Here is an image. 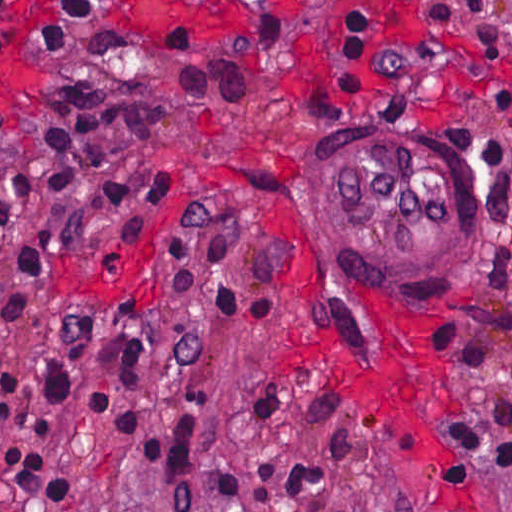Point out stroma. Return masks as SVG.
<instances>
[{"instance_id": "obj_1", "label": "stroma", "mask_w": 512, "mask_h": 512, "mask_svg": "<svg viewBox=\"0 0 512 512\" xmlns=\"http://www.w3.org/2000/svg\"><path fill=\"white\" fill-rule=\"evenodd\" d=\"M55 0H13L20 32ZM117 29L196 26L209 42L277 20L287 50L252 94L225 106H170L144 141L104 157L110 177L172 173L178 194L147 211L58 236L47 294L8 322L16 446L70 478L63 505L35 511L0 480V512H512V0H88ZM348 13L367 36L364 90H345L332 60ZM0 73L22 87L0 103L18 129L96 102L144 67L79 52L12 48ZM191 104H197L192 103ZM383 139L444 168L493 214V251L469 302L407 313L356 297L316 238L325 159L344 132ZM20 147L0 140V188ZM95 310V353L51 435H34L41 370ZM507 316L490 364L465 393L441 355L438 325L461 313ZM146 327L140 390L122 389L113 339ZM416 329L429 388V462H408L368 430L324 376L280 368L278 347L339 336L363 376L391 365L386 336ZM103 391L101 429L89 393ZM147 431L195 425L141 453L110 431L118 405ZM445 462L443 471L438 468Z\"/></svg>"}]
</instances>
